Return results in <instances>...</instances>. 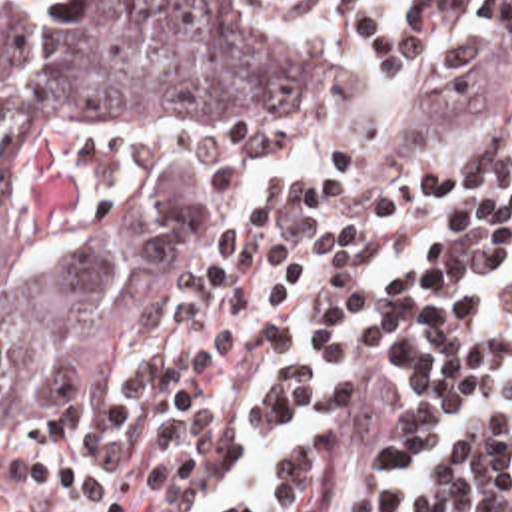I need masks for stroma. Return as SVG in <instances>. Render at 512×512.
<instances>
[{"mask_svg":"<svg viewBox=\"0 0 512 512\" xmlns=\"http://www.w3.org/2000/svg\"><path fill=\"white\" fill-rule=\"evenodd\" d=\"M149 1H215L277 22L319 66L325 98L237 126L77 140L29 170L33 248L141 278L145 322L127 356L0 430V512H73L151 388L159 344L233 262L406 194L466 148L478 116L458 0H432L414 58H388L293 0H0V24L91 20Z\"/></svg>","mask_w":512,"mask_h":512,"instance_id":"35a3bbf8","label":"stroma"}]
</instances>
